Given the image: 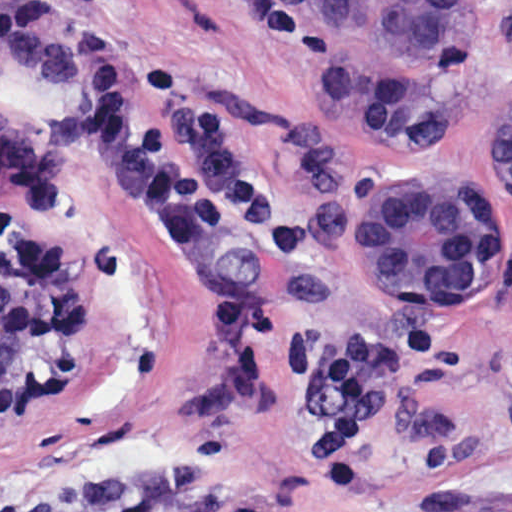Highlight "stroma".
Returning a JSON list of instances; mask_svg holds the SVG:
<instances>
[{"label":"stroma","instance_id":"35a3bbf8","mask_svg":"<svg viewBox=\"0 0 512 512\" xmlns=\"http://www.w3.org/2000/svg\"><path fill=\"white\" fill-rule=\"evenodd\" d=\"M116 18L138 74L167 55L227 109L297 227L166 235L109 190L73 111L0 59V262L37 244L60 283L48 357L0 394V512H512V190L490 152L512 109V0H488L465 107L417 140L350 130L288 0H148ZM396 177H449L495 212L498 283L476 311L402 313L362 270L357 201ZM222 288L250 292L297 335L391 337L411 319L441 330L365 447L364 488L319 478L317 390L261 343L249 383L220 385L193 321Z\"/></svg>","mask_w":512,"mask_h":512}]
</instances>
